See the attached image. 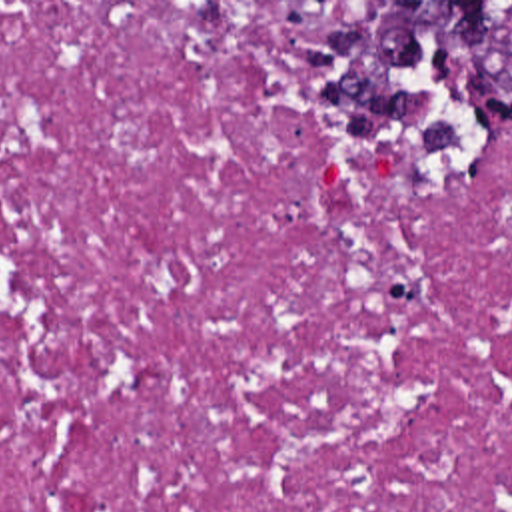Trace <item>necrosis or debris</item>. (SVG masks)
<instances>
[{
  "mask_svg": "<svg viewBox=\"0 0 512 512\" xmlns=\"http://www.w3.org/2000/svg\"><path fill=\"white\" fill-rule=\"evenodd\" d=\"M340 2H0V512H512V140L316 118Z\"/></svg>",
  "mask_w": 512,
  "mask_h": 512,
  "instance_id": "obj_1",
  "label": "necrosis or debris"
}]
</instances>
